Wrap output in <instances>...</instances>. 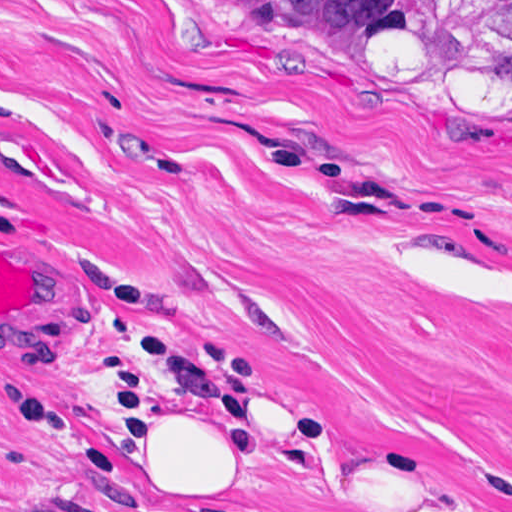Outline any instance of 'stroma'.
Wrapping results in <instances>:
<instances>
[{"label": "stroma", "instance_id": "obj_1", "mask_svg": "<svg viewBox=\"0 0 512 512\" xmlns=\"http://www.w3.org/2000/svg\"><path fill=\"white\" fill-rule=\"evenodd\" d=\"M22 138L0 250V512H512V105L353 84L241 0H0ZM185 361L220 475L173 491L82 408Z\"/></svg>", "mask_w": 512, "mask_h": 512}]
</instances>
